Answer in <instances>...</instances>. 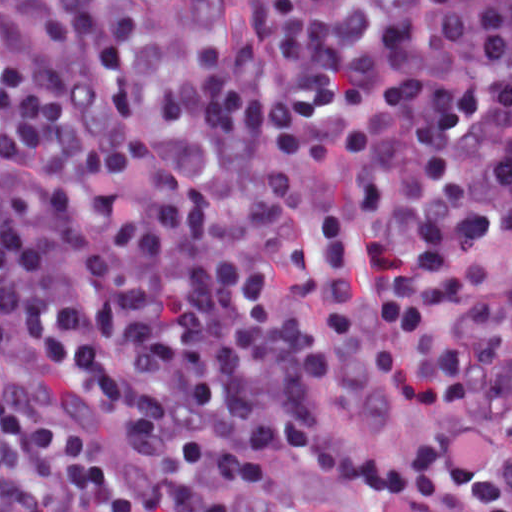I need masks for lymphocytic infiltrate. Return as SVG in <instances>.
<instances>
[{"mask_svg":"<svg viewBox=\"0 0 512 512\" xmlns=\"http://www.w3.org/2000/svg\"><path fill=\"white\" fill-rule=\"evenodd\" d=\"M369 309L410 454L323 418ZM288 455L512 512V0H1V512H244Z\"/></svg>","mask_w":512,"mask_h":512,"instance_id":"obj_1","label":"lymphocytic infiltrate"}]
</instances>
